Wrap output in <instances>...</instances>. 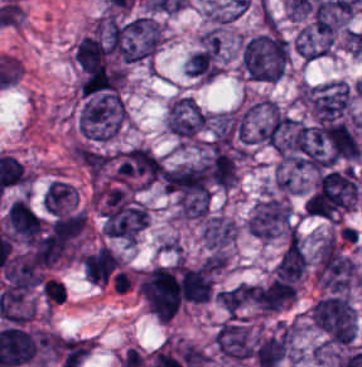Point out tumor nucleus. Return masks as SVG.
I'll return each mask as SVG.
<instances>
[{"instance_id": "5ab6c2c4", "label": "tumor nucleus", "mask_w": 362, "mask_h": 367, "mask_svg": "<svg viewBox=\"0 0 362 367\" xmlns=\"http://www.w3.org/2000/svg\"><path fill=\"white\" fill-rule=\"evenodd\" d=\"M208 117L191 97L178 95L170 105L167 128L180 140L189 143L205 130Z\"/></svg>"}, {"instance_id": "3d1891a8", "label": "tumor nucleus", "mask_w": 362, "mask_h": 367, "mask_svg": "<svg viewBox=\"0 0 362 367\" xmlns=\"http://www.w3.org/2000/svg\"><path fill=\"white\" fill-rule=\"evenodd\" d=\"M307 267L306 255L296 234L290 233L275 265L276 281H297Z\"/></svg>"}, {"instance_id": "2083b535", "label": "tumor nucleus", "mask_w": 362, "mask_h": 367, "mask_svg": "<svg viewBox=\"0 0 362 367\" xmlns=\"http://www.w3.org/2000/svg\"><path fill=\"white\" fill-rule=\"evenodd\" d=\"M42 205L47 214L62 215L78 207L76 189L66 181L53 180L42 196Z\"/></svg>"}, {"instance_id": "8643909e", "label": "tumor nucleus", "mask_w": 362, "mask_h": 367, "mask_svg": "<svg viewBox=\"0 0 362 367\" xmlns=\"http://www.w3.org/2000/svg\"><path fill=\"white\" fill-rule=\"evenodd\" d=\"M220 307L227 317L245 318L269 313L267 285L241 282L220 290Z\"/></svg>"}, {"instance_id": "2f306a5c", "label": "tumor nucleus", "mask_w": 362, "mask_h": 367, "mask_svg": "<svg viewBox=\"0 0 362 367\" xmlns=\"http://www.w3.org/2000/svg\"><path fill=\"white\" fill-rule=\"evenodd\" d=\"M311 321L330 343L350 344L357 331V313L346 296H326L315 302Z\"/></svg>"}, {"instance_id": "2cbd58db", "label": "tumor nucleus", "mask_w": 362, "mask_h": 367, "mask_svg": "<svg viewBox=\"0 0 362 367\" xmlns=\"http://www.w3.org/2000/svg\"><path fill=\"white\" fill-rule=\"evenodd\" d=\"M334 45L332 32L316 21L303 26L294 38V48L298 55L310 61L333 52Z\"/></svg>"}]
</instances>
